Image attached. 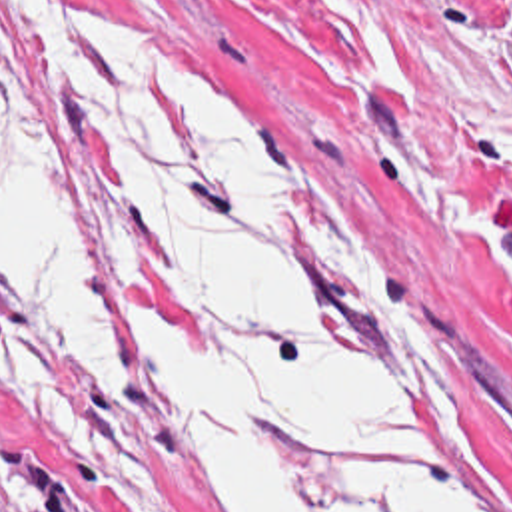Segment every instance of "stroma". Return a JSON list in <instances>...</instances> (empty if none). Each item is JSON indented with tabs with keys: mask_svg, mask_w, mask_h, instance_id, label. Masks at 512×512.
<instances>
[{
	"mask_svg": "<svg viewBox=\"0 0 512 512\" xmlns=\"http://www.w3.org/2000/svg\"><path fill=\"white\" fill-rule=\"evenodd\" d=\"M80 2L138 24L287 156L299 248L429 477L461 512H512V0H363L413 90L367 66L331 0ZM0 18L116 290L100 168L68 134L16 0H0ZM0 322L104 479L0 386V512H202L156 454L136 372L132 410L2 290Z\"/></svg>",
	"mask_w": 512,
	"mask_h": 512,
	"instance_id": "35a3bbf8",
	"label": "stroma"
}]
</instances>
